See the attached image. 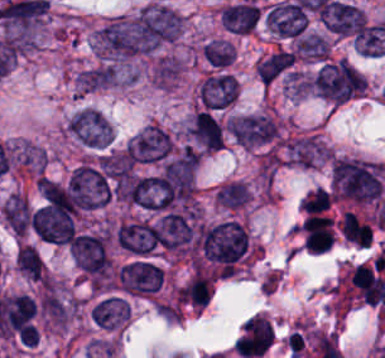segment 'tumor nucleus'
I'll return each mask as SVG.
<instances>
[{
    "label": "tumor nucleus",
    "mask_w": 385,
    "mask_h": 358,
    "mask_svg": "<svg viewBox=\"0 0 385 358\" xmlns=\"http://www.w3.org/2000/svg\"><path fill=\"white\" fill-rule=\"evenodd\" d=\"M384 175V162L335 158L331 164L332 193L352 201H372L381 191Z\"/></svg>",
    "instance_id": "tumor-nucleus-1"
},
{
    "label": "tumor nucleus",
    "mask_w": 385,
    "mask_h": 358,
    "mask_svg": "<svg viewBox=\"0 0 385 358\" xmlns=\"http://www.w3.org/2000/svg\"><path fill=\"white\" fill-rule=\"evenodd\" d=\"M197 246L202 258L226 271H234L249 246L246 230L235 220L197 227Z\"/></svg>",
    "instance_id": "tumor-nucleus-2"
},
{
    "label": "tumor nucleus",
    "mask_w": 385,
    "mask_h": 358,
    "mask_svg": "<svg viewBox=\"0 0 385 358\" xmlns=\"http://www.w3.org/2000/svg\"><path fill=\"white\" fill-rule=\"evenodd\" d=\"M313 92L330 101H343L365 92L364 76L345 60L322 62L313 74Z\"/></svg>",
    "instance_id": "tumor-nucleus-3"
},
{
    "label": "tumor nucleus",
    "mask_w": 385,
    "mask_h": 358,
    "mask_svg": "<svg viewBox=\"0 0 385 358\" xmlns=\"http://www.w3.org/2000/svg\"><path fill=\"white\" fill-rule=\"evenodd\" d=\"M66 189L78 210L105 206L111 199L107 176L93 162L78 164L68 178Z\"/></svg>",
    "instance_id": "tumor-nucleus-4"
},
{
    "label": "tumor nucleus",
    "mask_w": 385,
    "mask_h": 358,
    "mask_svg": "<svg viewBox=\"0 0 385 358\" xmlns=\"http://www.w3.org/2000/svg\"><path fill=\"white\" fill-rule=\"evenodd\" d=\"M67 127L92 148H102L110 143V124L97 108L84 106L71 115Z\"/></svg>",
    "instance_id": "tumor-nucleus-5"
},
{
    "label": "tumor nucleus",
    "mask_w": 385,
    "mask_h": 358,
    "mask_svg": "<svg viewBox=\"0 0 385 358\" xmlns=\"http://www.w3.org/2000/svg\"><path fill=\"white\" fill-rule=\"evenodd\" d=\"M274 341L272 323L268 317L249 316L235 341V350L247 358L263 356Z\"/></svg>",
    "instance_id": "tumor-nucleus-6"
},
{
    "label": "tumor nucleus",
    "mask_w": 385,
    "mask_h": 358,
    "mask_svg": "<svg viewBox=\"0 0 385 358\" xmlns=\"http://www.w3.org/2000/svg\"><path fill=\"white\" fill-rule=\"evenodd\" d=\"M68 248L77 268L89 273H103L109 263L103 236L77 234Z\"/></svg>",
    "instance_id": "tumor-nucleus-7"
},
{
    "label": "tumor nucleus",
    "mask_w": 385,
    "mask_h": 358,
    "mask_svg": "<svg viewBox=\"0 0 385 358\" xmlns=\"http://www.w3.org/2000/svg\"><path fill=\"white\" fill-rule=\"evenodd\" d=\"M140 14L155 48L178 34V14L166 6L150 5Z\"/></svg>",
    "instance_id": "tumor-nucleus-8"
},
{
    "label": "tumor nucleus",
    "mask_w": 385,
    "mask_h": 358,
    "mask_svg": "<svg viewBox=\"0 0 385 358\" xmlns=\"http://www.w3.org/2000/svg\"><path fill=\"white\" fill-rule=\"evenodd\" d=\"M325 159H327L326 145L309 135L288 139L284 144L286 163L309 168Z\"/></svg>",
    "instance_id": "tumor-nucleus-9"
},
{
    "label": "tumor nucleus",
    "mask_w": 385,
    "mask_h": 358,
    "mask_svg": "<svg viewBox=\"0 0 385 358\" xmlns=\"http://www.w3.org/2000/svg\"><path fill=\"white\" fill-rule=\"evenodd\" d=\"M265 19L278 34L295 35L303 30L305 13L298 1L283 0L270 7Z\"/></svg>",
    "instance_id": "tumor-nucleus-10"
},
{
    "label": "tumor nucleus",
    "mask_w": 385,
    "mask_h": 358,
    "mask_svg": "<svg viewBox=\"0 0 385 358\" xmlns=\"http://www.w3.org/2000/svg\"><path fill=\"white\" fill-rule=\"evenodd\" d=\"M38 210L52 215H72L73 201L65 189L45 178L38 177Z\"/></svg>",
    "instance_id": "tumor-nucleus-11"
},
{
    "label": "tumor nucleus",
    "mask_w": 385,
    "mask_h": 358,
    "mask_svg": "<svg viewBox=\"0 0 385 358\" xmlns=\"http://www.w3.org/2000/svg\"><path fill=\"white\" fill-rule=\"evenodd\" d=\"M226 129L241 145L247 146L269 136V119L263 115H243L226 121Z\"/></svg>",
    "instance_id": "tumor-nucleus-12"
},
{
    "label": "tumor nucleus",
    "mask_w": 385,
    "mask_h": 358,
    "mask_svg": "<svg viewBox=\"0 0 385 358\" xmlns=\"http://www.w3.org/2000/svg\"><path fill=\"white\" fill-rule=\"evenodd\" d=\"M220 20L225 30L238 34L251 32L256 26L254 3L243 0L226 5L220 11Z\"/></svg>",
    "instance_id": "tumor-nucleus-13"
},
{
    "label": "tumor nucleus",
    "mask_w": 385,
    "mask_h": 358,
    "mask_svg": "<svg viewBox=\"0 0 385 358\" xmlns=\"http://www.w3.org/2000/svg\"><path fill=\"white\" fill-rule=\"evenodd\" d=\"M91 312L95 324L101 328H115L126 319L125 298L108 294L91 306Z\"/></svg>",
    "instance_id": "tumor-nucleus-14"
},
{
    "label": "tumor nucleus",
    "mask_w": 385,
    "mask_h": 358,
    "mask_svg": "<svg viewBox=\"0 0 385 358\" xmlns=\"http://www.w3.org/2000/svg\"><path fill=\"white\" fill-rule=\"evenodd\" d=\"M187 131L206 148H220L222 144L219 122L204 110L196 111Z\"/></svg>",
    "instance_id": "tumor-nucleus-15"
},
{
    "label": "tumor nucleus",
    "mask_w": 385,
    "mask_h": 358,
    "mask_svg": "<svg viewBox=\"0 0 385 358\" xmlns=\"http://www.w3.org/2000/svg\"><path fill=\"white\" fill-rule=\"evenodd\" d=\"M212 290V283L206 274L193 273L179 288V303L193 308L206 305Z\"/></svg>",
    "instance_id": "tumor-nucleus-16"
},
{
    "label": "tumor nucleus",
    "mask_w": 385,
    "mask_h": 358,
    "mask_svg": "<svg viewBox=\"0 0 385 358\" xmlns=\"http://www.w3.org/2000/svg\"><path fill=\"white\" fill-rule=\"evenodd\" d=\"M293 62V53L275 52L255 63V76L268 85Z\"/></svg>",
    "instance_id": "tumor-nucleus-17"
},
{
    "label": "tumor nucleus",
    "mask_w": 385,
    "mask_h": 358,
    "mask_svg": "<svg viewBox=\"0 0 385 358\" xmlns=\"http://www.w3.org/2000/svg\"><path fill=\"white\" fill-rule=\"evenodd\" d=\"M116 77L113 69L107 65L86 68L76 75V88L78 91L90 92L110 85Z\"/></svg>",
    "instance_id": "tumor-nucleus-18"
},
{
    "label": "tumor nucleus",
    "mask_w": 385,
    "mask_h": 358,
    "mask_svg": "<svg viewBox=\"0 0 385 358\" xmlns=\"http://www.w3.org/2000/svg\"><path fill=\"white\" fill-rule=\"evenodd\" d=\"M250 191L246 183L233 181L220 187L216 193L215 202L217 206L228 209L244 207Z\"/></svg>",
    "instance_id": "tumor-nucleus-19"
},
{
    "label": "tumor nucleus",
    "mask_w": 385,
    "mask_h": 358,
    "mask_svg": "<svg viewBox=\"0 0 385 358\" xmlns=\"http://www.w3.org/2000/svg\"><path fill=\"white\" fill-rule=\"evenodd\" d=\"M15 264L18 270L25 276L40 280L43 263L38 251L29 245H22L18 248Z\"/></svg>",
    "instance_id": "tumor-nucleus-20"
},
{
    "label": "tumor nucleus",
    "mask_w": 385,
    "mask_h": 358,
    "mask_svg": "<svg viewBox=\"0 0 385 358\" xmlns=\"http://www.w3.org/2000/svg\"><path fill=\"white\" fill-rule=\"evenodd\" d=\"M295 51L302 57L326 58L328 44L321 34L308 33L298 39Z\"/></svg>",
    "instance_id": "tumor-nucleus-21"
}]
</instances>
